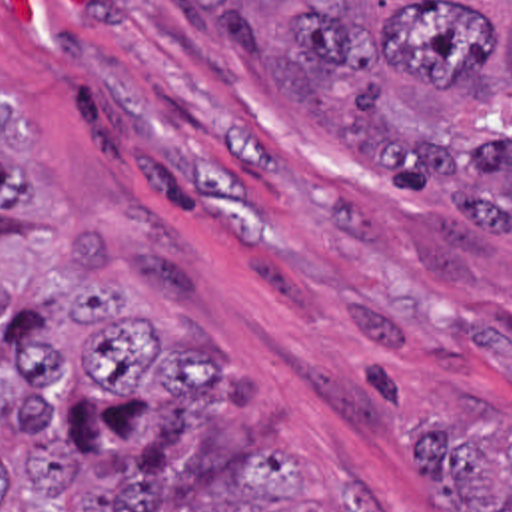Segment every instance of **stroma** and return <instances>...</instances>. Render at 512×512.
Returning a JSON list of instances; mask_svg holds the SVG:
<instances>
[{
	"label": "stroma",
	"instance_id": "35a3bbf8",
	"mask_svg": "<svg viewBox=\"0 0 512 512\" xmlns=\"http://www.w3.org/2000/svg\"><path fill=\"white\" fill-rule=\"evenodd\" d=\"M0 91L40 147V215L0 227V279L70 303L68 233L95 229L127 307L217 358L233 420L173 440L163 482L207 488L259 444L311 450L263 512H455L411 464L413 422L512 418V251L477 297L407 227L449 191H397L267 93L165 0H0Z\"/></svg>",
	"mask_w": 512,
	"mask_h": 512
}]
</instances>
